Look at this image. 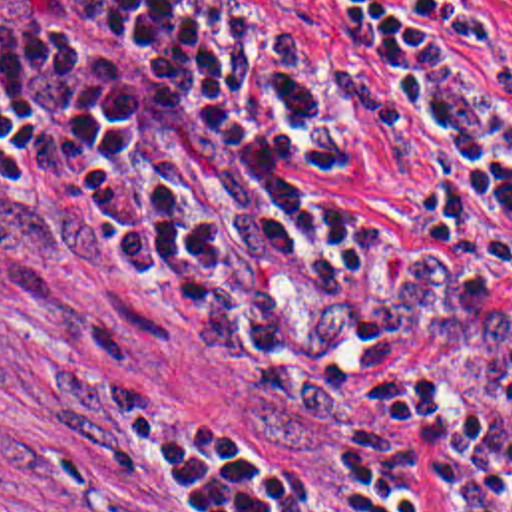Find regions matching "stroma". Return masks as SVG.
Returning a JSON list of instances; mask_svg holds the SVG:
<instances>
[{
    "instance_id": "obj_1",
    "label": "stroma",
    "mask_w": 512,
    "mask_h": 512,
    "mask_svg": "<svg viewBox=\"0 0 512 512\" xmlns=\"http://www.w3.org/2000/svg\"><path fill=\"white\" fill-rule=\"evenodd\" d=\"M230 51L299 27L278 0H182ZM512 57V0H463ZM154 429L212 461L280 451L250 385L62 260L0 254V512H224ZM313 512H341L333 495Z\"/></svg>"
}]
</instances>
